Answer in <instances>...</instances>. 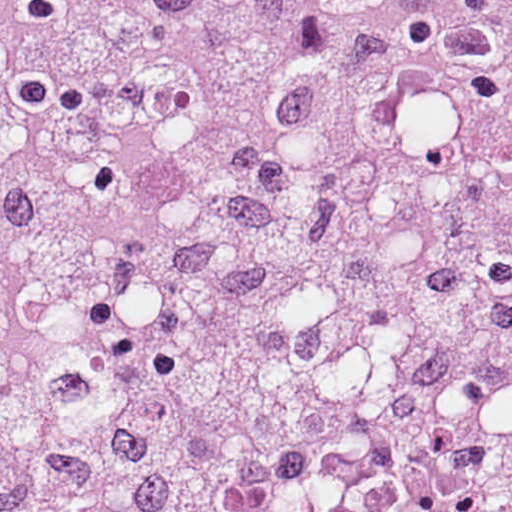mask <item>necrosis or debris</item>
I'll use <instances>...</instances> for the list:
<instances>
[{
    "label": "necrosis or debris",
    "instance_id": "1",
    "mask_svg": "<svg viewBox=\"0 0 512 512\" xmlns=\"http://www.w3.org/2000/svg\"><path fill=\"white\" fill-rule=\"evenodd\" d=\"M0 512H512V0H0Z\"/></svg>",
    "mask_w": 512,
    "mask_h": 512
}]
</instances>
